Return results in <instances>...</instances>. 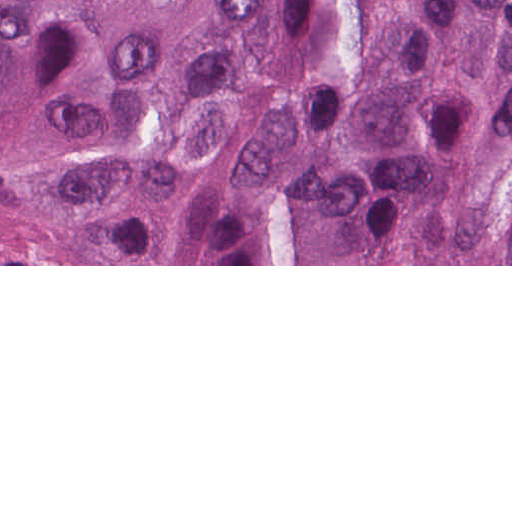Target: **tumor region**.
Segmentation results:
<instances>
[{
    "instance_id": "1",
    "label": "tumor region",
    "mask_w": 512,
    "mask_h": 512,
    "mask_svg": "<svg viewBox=\"0 0 512 512\" xmlns=\"http://www.w3.org/2000/svg\"><path fill=\"white\" fill-rule=\"evenodd\" d=\"M0 264H512V0H0Z\"/></svg>"
}]
</instances>
